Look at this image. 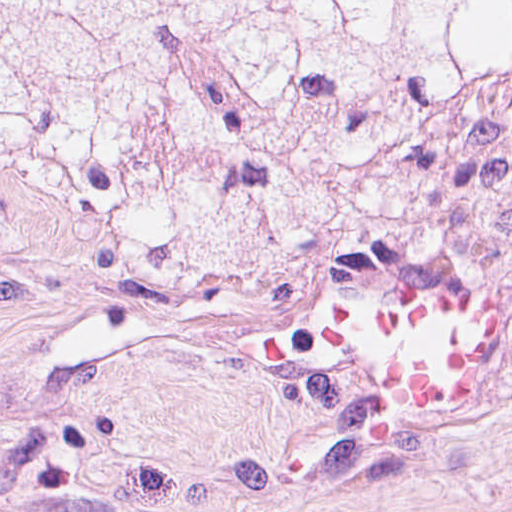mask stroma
<instances>
[{"mask_svg": "<svg viewBox=\"0 0 512 512\" xmlns=\"http://www.w3.org/2000/svg\"><path fill=\"white\" fill-rule=\"evenodd\" d=\"M380 177L363 219L290 206L254 270L136 249L75 208L0 227V512H512V241L463 205L450 154ZM358 267L490 293L476 412L397 431L300 347Z\"/></svg>", "mask_w": 512, "mask_h": 512, "instance_id": "35a3bbf8", "label": "stroma"}]
</instances>
